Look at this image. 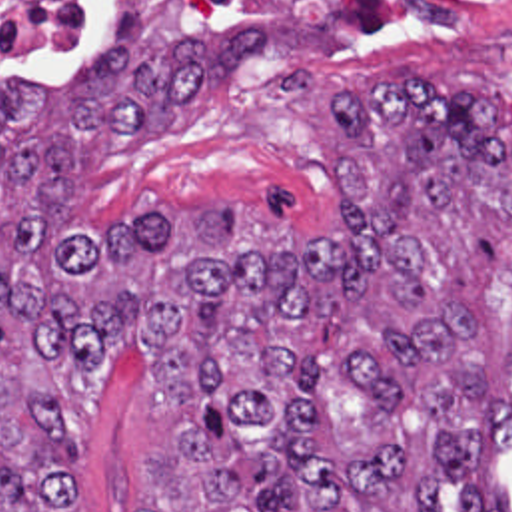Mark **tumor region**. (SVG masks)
<instances>
[{"label":"tumor region","mask_w":512,"mask_h":512,"mask_svg":"<svg viewBox=\"0 0 512 512\" xmlns=\"http://www.w3.org/2000/svg\"><path fill=\"white\" fill-rule=\"evenodd\" d=\"M153 1H113L77 79H0V512H71L63 377L119 347L157 357L139 512H445L465 478V512H512L497 472L471 476L512 444L509 99L427 71L341 93L331 225L175 199L97 233L75 197L93 131L175 121L269 43L155 45Z\"/></svg>","instance_id":"tumor-region-1"}]
</instances>
